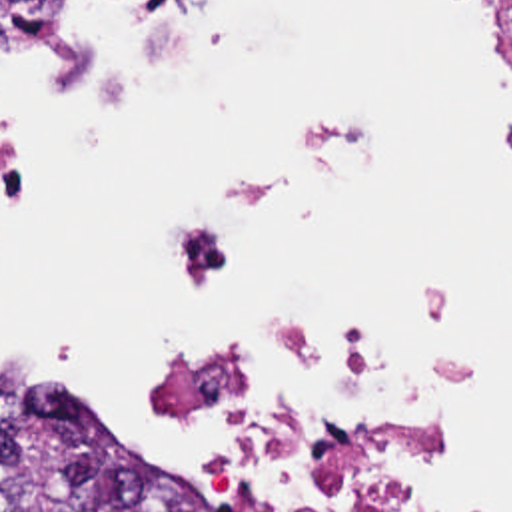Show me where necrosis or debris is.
Returning <instances> with one entry per match:
<instances>
[{
  "label": "necrosis or debris",
  "instance_id": "4bbe7bcc",
  "mask_svg": "<svg viewBox=\"0 0 512 512\" xmlns=\"http://www.w3.org/2000/svg\"><path fill=\"white\" fill-rule=\"evenodd\" d=\"M52 0H0V53H54L42 9ZM512 35V0H493ZM357 129L312 123L296 135V161L264 183L220 187V213L186 237L180 273L214 285L226 265L222 223L278 189L308 157L353 153ZM162 408L214 444L222 460H246L278 478L286 512H445L413 480L411 456L437 430L439 406L407 360L365 356L331 342L276 340L192 360L166 374Z\"/></svg>",
  "mask_w": 512,
  "mask_h": 512
}]
</instances>
